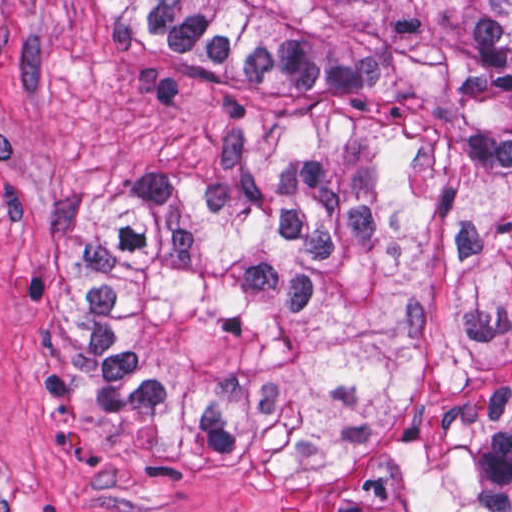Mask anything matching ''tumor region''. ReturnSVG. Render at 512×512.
Masks as SVG:
<instances>
[{
  "label": "tumor region",
  "instance_id": "obj_1",
  "mask_svg": "<svg viewBox=\"0 0 512 512\" xmlns=\"http://www.w3.org/2000/svg\"><path fill=\"white\" fill-rule=\"evenodd\" d=\"M297 133L83 199L33 381L125 459L512 511V0H108Z\"/></svg>",
  "mask_w": 512,
  "mask_h": 512
}]
</instances>
